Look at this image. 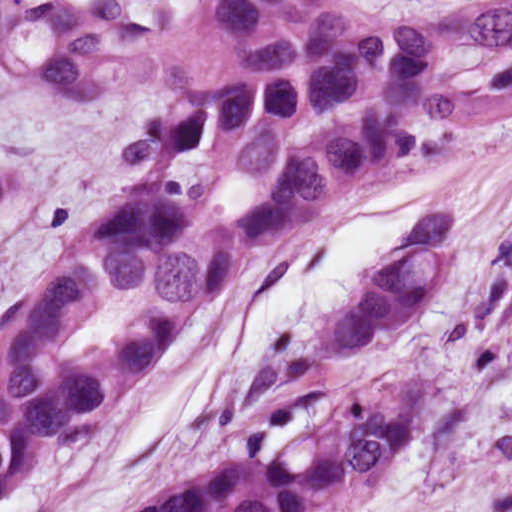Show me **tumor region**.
I'll return each mask as SVG.
<instances>
[{
    "label": "tumor region",
    "mask_w": 512,
    "mask_h": 512,
    "mask_svg": "<svg viewBox=\"0 0 512 512\" xmlns=\"http://www.w3.org/2000/svg\"><path fill=\"white\" fill-rule=\"evenodd\" d=\"M512 126V0H0V504L184 356L252 267L381 169ZM428 211L321 329L358 353L445 286ZM405 376V375H404ZM404 376L338 395L284 457L124 512H345L421 414Z\"/></svg>",
    "instance_id": "tumor-region-1"
}]
</instances>
